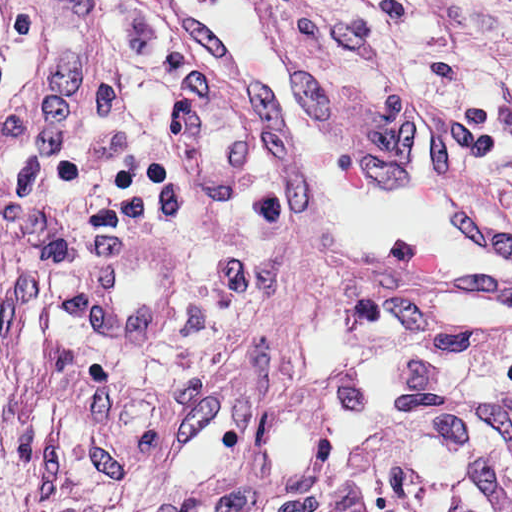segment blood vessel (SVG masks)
<instances>
[{"instance_id":"8fb6f2fc","label":"blood vessel","mask_w":512,"mask_h":512,"mask_svg":"<svg viewBox=\"0 0 512 512\" xmlns=\"http://www.w3.org/2000/svg\"><path fill=\"white\" fill-rule=\"evenodd\" d=\"M233 102L349 291L512 311V215L437 109L408 95L396 166L352 151L278 0H150Z\"/></svg>"}]
</instances>
